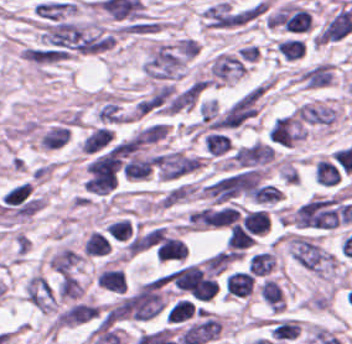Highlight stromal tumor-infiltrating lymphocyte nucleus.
Instances as JSON below:
<instances>
[{
	"label": "stromal tumor-infiltrating lymphocyte nucleus",
	"mask_w": 352,
	"mask_h": 344,
	"mask_svg": "<svg viewBox=\"0 0 352 344\" xmlns=\"http://www.w3.org/2000/svg\"><path fill=\"white\" fill-rule=\"evenodd\" d=\"M95 284L115 293H122L125 280L119 268L102 267L95 276Z\"/></svg>",
	"instance_id": "stromal-tumor-infiltrating-lymphocyte-nucleus-6"
},
{
	"label": "stromal tumor-infiltrating lymphocyte nucleus",
	"mask_w": 352,
	"mask_h": 344,
	"mask_svg": "<svg viewBox=\"0 0 352 344\" xmlns=\"http://www.w3.org/2000/svg\"><path fill=\"white\" fill-rule=\"evenodd\" d=\"M293 114L296 118L311 123L328 125L333 122L337 113L331 106H325L310 102H302L295 108Z\"/></svg>",
	"instance_id": "stromal-tumor-infiltrating-lymphocyte-nucleus-3"
},
{
	"label": "stromal tumor-infiltrating lymphocyte nucleus",
	"mask_w": 352,
	"mask_h": 344,
	"mask_svg": "<svg viewBox=\"0 0 352 344\" xmlns=\"http://www.w3.org/2000/svg\"><path fill=\"white\" fill-rule=\"evenodd\" d=\"M214 82L229 83L245 72V66L238 57L227 51H219L209 64Z\"/></svg>",
	"instance_id": "stromal-tumor-infiltrating-lymphocyte-nucleus-1"
},
{
	"label": "stromal tumor-infiltrating lymphocyte nucleus",
	"mask_w": 352,
	"mask_h": 344,
	"mask_svg": "<svg viewBox=\"0 0 352 344\" xmlns=\"http://www.w3.org/2000/svg\"><path fill=\"white\" fill-rule=\"evenodd\" d=\"M253 241V237L238 225H234L226 240V248L241 251Z\"/></svg>",
	"instance_id": "stromal-tumor-infiltrating-lymphocyte-nucleus-17"
},
{
	"label": "stromal tumor-infiltrating lymphocyte nucleus",
	"mask_w": 352,
	"mask_h": 344,
	"mask_svg": "<svg viewBox=\"0 0 352 344\" xmlns=\"http://www.w3.org/2000/svg\"><path fill=\"white\" fill-rule=\"evenodd\" d=\"M69 134V127L56 123L38 138V144L46 149L59 148L68 139Z\"/></svg>",
	"instance_id": "stromal-tumor-infiltrating-lymphocyte-nucleus-11"
},
{
	"label": "stromal tumor-infiltrating lymphocyte nucleus",
	"mask_w": 352,
	"mask_h": 344,
	"mask_svg": "<svg viewBox=\"0 0 352 344\" xmlns=\"http://www.w3.org/2000/svg\"><path fill=\"white\" fill-rule=\"evenodd\" d=\"M0 201L6 206H31L29 184L18 183L4 192Z\"/></svg>",
	"instance_id": "stromal-tumor-infiltrating-lymphocyte-nucleus-9"
},
{
	"label": "stromal tumor-infiltrating lymphocyte nucleus",
	"mask_w": 352,
	"mask_h": 344,
	"mask_svg": "<svg viewBox=\"0 0 352 344\" xmlns=\"http://www.w3.org/2000/svg\"><path fill=\"white\" fill-rule=\"evenodd\" d=\"M95 118L100 122L119 123L126 122L127 117L114 100H107L98 107Z\"/></svg>",
	"instance_id": "stromal-tumor-infiltrating-lymphocyte-nucleus-14"
},
{
	"label": "stromal tumor-infiltrating lymphocyte nucleus",
	"mask_w": 352,
	"mask_h": 344,
	"mask_svg": "<svg viewBox=\"0 0 352 344\" xmlns=\"http://www.w3.org/2000/svg\"><path fill=\"white\" fill-rule=\"evenodd\" d=\"M340 173L331 160L317 159L314 168V179L322 185L337 183Z\"/></svg>",
	"instance_id": "stromal-tumor-infiltrating-lymphocyte-nucleus-13"
},
{
	"label": "stromal tumor-infiltrating lymphocyte nucleus",
	"mask_w": 352,
	"mask_h": 344,
	"mask_svg": "<svg viewBox=\"0 0 352 344\" xmlns=\"http://www.w3.org/2000/svg\"><path fill=\"white\" fill-rule=\"evenodd\" d=\"M110 138L109 127L97 126L77 144L78 150L84 154H91L108 144Z\"/></svg>",
	"instance_id": "stromal-tumor-infiltrating-lymphocyte-nucleus-5"
},
{
	"label": "stromal tumor-infiltrating lymphocyte nucleus",
	"mask_w": 352,
	"mask_h": 344,
	"mask_svg": "<svg viewBox=\"0 0 352 344\" xmlns=\"http://www.w3.org/2000/svg\"><path fill=\"white\" fill-rule=\"evenodd\" d=\"M111 240L125 241L131 236L132 226L127 219H120L113 222H109L105 229Z\"/></svg>",
	"instance_id": "stromal-tumor-infiltrating-lymphocyte-nucleus-18"
},
{
	"label": "stromal tumor-infiltrating lymphocyte nucleus",
	"mask_w": 352,
	"mask_h": 344,
	"mask_svg": "<svg viewBox=\"0 0 352 344\" xmlns=\"http://www.w3.org/2000/svg\"><path fill=\"white\" fill-rule=\"evenodd\" d=\"M352 31L351 8H340L324 23L316 34L317 42L338 40Z\"/></svg>",
	"instance_id": "stromal-tumor-infiltrating-lymphocyte-nucleus-2"
},
{
	"label": "stromal tumor-infiltrating lymphocyte nucleus",
	"mask_w": 352,
	"mask_h": 344,
	"mask_svg": "<svg viewBox=\"0 0 352 344\" xmlns=\"http://www.w3.org/2000/svg\"><path fill=\"white\" fill-rule=\"evenodd\" d=\"M243 227L250 235H264L269 227L265 211L247 210L240 219Z\"/></svg>",
	"instance_id": "stromal-tumor-infiltrating-lymphocyte-nucleus-8"
},
{
	"label": "stromal tumor-infiltrating lymphocyte nucleus",
	"mask_w": 352,
	"mask_h": 344,
	"mask_svg": "<svg viewBox=\"0 0 352 344\" xmlns=\"http://www.w3.org/2000/svg\"><path fill=\"white\" fill-rule=\"evenodd\" d=\"M110 248L108 239L98 231H90L82 245V253L89 257L106 256Z\"/></svg>",
	"instance_id": "stromal-tumor-infiltrating-lymphocyte-nucleus-12"
},
{
	"label": "stromal tumor-infiltrating lymphocyte nucleus",
	"mask_w": 352,
	"mask_h": 344,
	"mask_svg": "<svg viewBox=\"0 0 352 344\" xmlns=\"http://www.w3.org/2000/svg\"><path fill=\"white\" fill-rule=\"evenodd\" d=\"M275 49L285 60H295L302 56L305 45L302 39L284 38L276 43Z\"/></svg>",
	"instance_id": "stromal-tumor-infiltrating-lymphocyte-nucleus-15"
},
{
	"label": "stromal tumor-infiltrating lymphocyte nucleus",
	"mask_w": 352,
	"mask_h": 344,
	"mask_svg": "<svg viewBox=\"0 0 352 344\" xmlns=\"http://www.w3.org/2000/svg\"><path fill=\"white\" fill-rule=\"evenodd\" d=\"M274 266V253L269 250L254 253L247 261V269L253 276H266Z\"/></svg>",
	"instance_id": "stromal-tumor-infiltrating-lymphocyte-nucleus-10"
},
{
	"label": "stromal tumor-infiltrating lymphocyte nucleus",
	"mask_w": 352,
	"mask_h": 344,
	"mask_svg": "<svg viewBox=\"0 0 352 344\" xmlns=\"http://www.w3.org/2000/svg\"><path fill=\"white\" fill-rule=\"evenodd\" d=\"M258 292L260 299L269 310L282 311L284 301L280 286L275 279L264 278L259 284Z\"/></svg>",
	"instance_id": "stromal-tumor-infiltrating-lymphocyte-nucleus-4"
},
{
	"label": "stromal tumor-infiltrating lymphocyte nucleus",
	"mask_w": 352,
	"mask_h": 344,
	"mask_svg": "<svg viewBox=\"0 0 352 344\" xmlns=\"http://www.w3.org/2000/svg\"><path fill=\"white\" fill-rule=\"evenodd\" d=\"M187 250L183 242L164 237L155 248V256L162 261H179L184 258Z\"/></svg>",
	"instance_id": "stromal-tumor-infiltrating-lymphocyte-nucleus-7"
},
{
	"label": "stromal tumor-infiltrating lymphocyte nucleus",
	"mask_w": 352,
	"mask_h": 344,
	"mask_svg": "<svg viewBox=\"0 0 352 344\" xmlns=\"http://www.w3.org/2000/svg\"><path fill=\"white\" fill-rule=\"evenodd\" d=\"M209 154L220 155L227 152L230 145L227 134L223 132H209L203 141Z\"/></svg>",
	"instance_id": "stromal-tumor-infiltrating-lymphocyte-nucleus-16"
}]
</instances>
